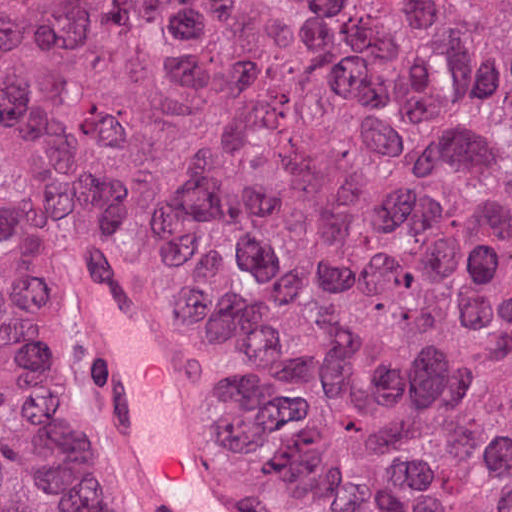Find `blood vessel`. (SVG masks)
Returning <instances> with one entry per match:
<instances>
[{
	"label": "blood vessel",
	"instance_id": "blood-vessel-1",
	"mask_svg": "<svg viewBox=\"0 0 512 512\" xmlns=\"http://www.w3.org/2000/svg\"><path fill=\"white\" fill-rule=\"evenodd\" d=\"M101 451L143 512H266L226 474L154 343L134 285L94 248L73 261Z\"/></svg>",
	"mask_w": 512,
	"mask_h": 512
}]
</instances>
